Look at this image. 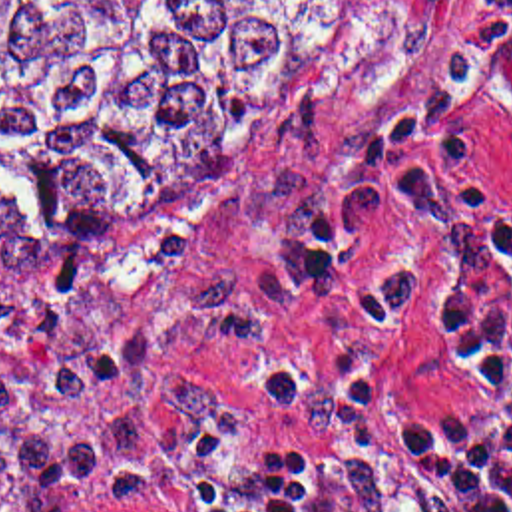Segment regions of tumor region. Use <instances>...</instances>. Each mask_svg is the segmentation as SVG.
<instances>
[{"label":"tumor region","mask_w":512,"mask_h":512,"mask_svg":"<svg viewBox=\"0 0 512 512\" xmlns=\"http://www.w3.org/2000/svg\"><path fill=\"white\" fill-rule=\"evenodd\" d=\"M368 0H0V261L83 253L188 209L302 103ZM61 259L45 298L0 304V494L129 468L234 406L170 338L260 346L278 312L240 271L131 302Z\"/></svg>","instance_id":"1"}]
</instances>
